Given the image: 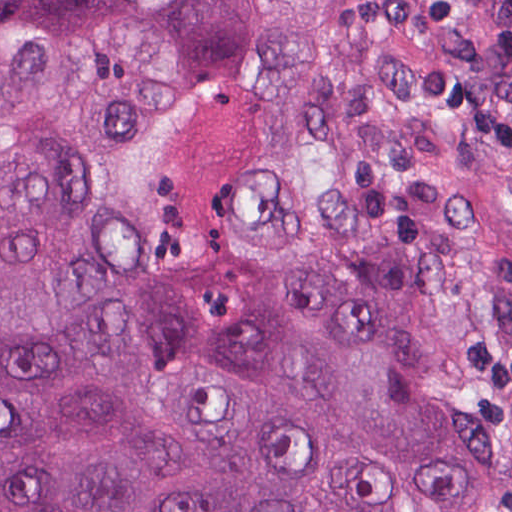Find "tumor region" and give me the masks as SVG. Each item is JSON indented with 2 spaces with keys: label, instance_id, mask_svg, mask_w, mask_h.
Returning a JSON list of instances; mask_svg holds the SVG:
<instances>
[{
  "label": "tumor region",
  "instance_id": "1",
  "mask_svg": "<svg viewBox=\"0 0 512 512\" xmlns=\"http://www.w3.org/2000/svg\"><path fill=\"white\" fill-rule=\"evenodd\" d=\"M431 366L512 512V0H0V512H395Z\"/></svg>",
  "mask_w": 512,
  "mask_h": 512
}]
</instances>
